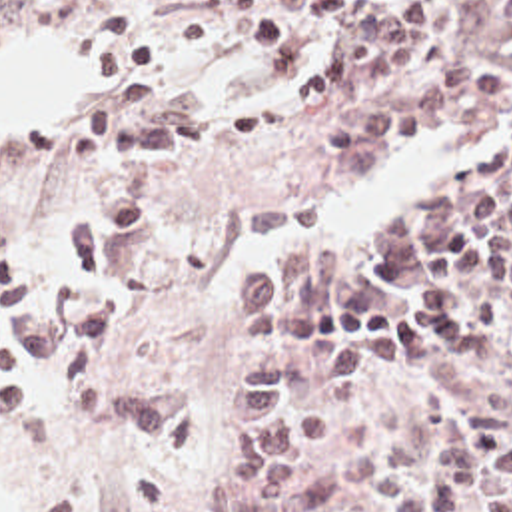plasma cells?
<instances>
[{
    "label": "plasma cells",
    "instance_id": "9512152a",
    "mask_svg": "<svg viewBox=\"0 0 512 512\" xmlns=\"http://www.w3.org/2000/svg\"><path fill=\"white\" fill-rule=\"evenodd\" d=\"M457 0H200L182 35L188 45L226 19L262 55L269 77L297 69L317 25L339 35L329 59L285 87L293 109H323L345 87L409 67ZM138 75L94 95L68 127L74 163L126 159L124 181L72 219L44 281L26 275L18 251H0V373L50 371L84 419L110 417L140 438H172L196 425V403L178 387L116 385L96 367L130 319V303L104 291L70 303L74 283L104 275L110 251L144 235L158 203V157L176 147L250 145L279 129V107L252 103L216 121L184 109H148ZM512 117V85L489 71L457 69L377 99L317 129L333 153L375 155L427 129ZM238 349L295 347V365L265 363L236 389L242 456L214 488L212 512H285L307 462L337 438L321 411L289 397L335 401L403 373L409 349L461 379L512 369V135L509 147L437 199L407 211L355 249H311L234 297ZM343 482L387 512H512V440L487 448L467 407L441 413L429 466L379 440L343 448ZM138 512H178L156 474L134 476Z\"/></svg>",
    "mask_w": 512,
    "mask_h": 512
}]
</instances>
